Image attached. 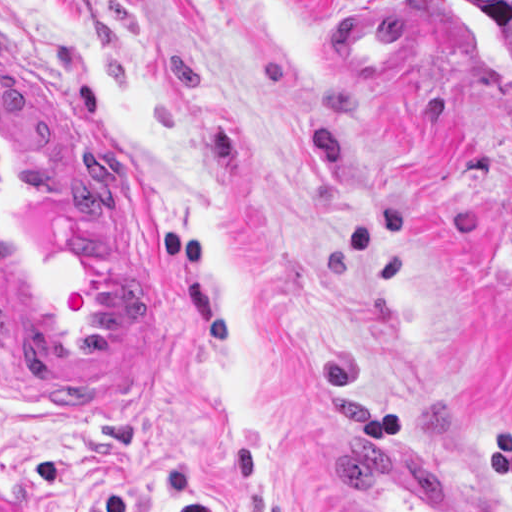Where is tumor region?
Returning <instances> with one entry per match:
<instances>
[{
  "instance_id": "obj_1",
  "label": "tumor region",
  "mask_w": 512,
  "mask_h": 512,
  "mask_svg": "<svg viewBox=\"0 0 512 512\" xmlns=\"http://www.w3.org/2000/svg\"><path fill=\"white\" fill-rule=\"evenodd\" d=\"M472 15L501 30L512 41V0H458Z\"/></svg>"
}]
</instances>
